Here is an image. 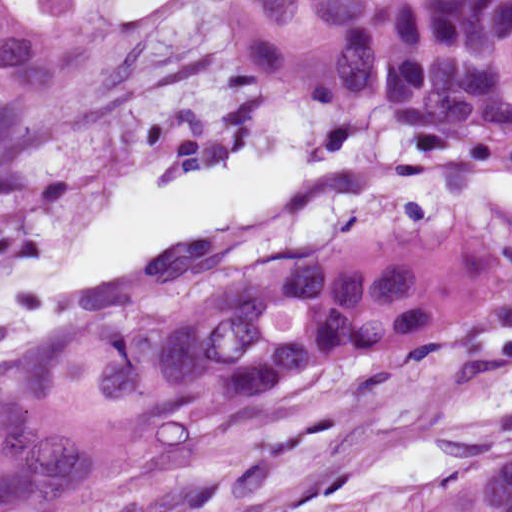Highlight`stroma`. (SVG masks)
Returning <instances> with one entry per match:
<instances>
[{"instance_id":"obj_1","label":"stroma","mask_w":512,"mask_h":512,"mask_svg":"<svg viewBox=\"0 0 512 512\" xmlns=\"http://www.w3.org/2000/svg\"><path fill=\"white\" fill-rule=\"evenodd\" d=\"M79 22L58 93L0 150V365L179 268L254 256L512 140V0H428L369 33L314 94L236 76L225 48L231 0H167L112 20L102 0ZM159 31V33H157ZM297 113L307 159L353 154L262 219L176 247L52 298L54 278L125 172L170 152L177 183Z\"/></svg>"}]
</instances>
